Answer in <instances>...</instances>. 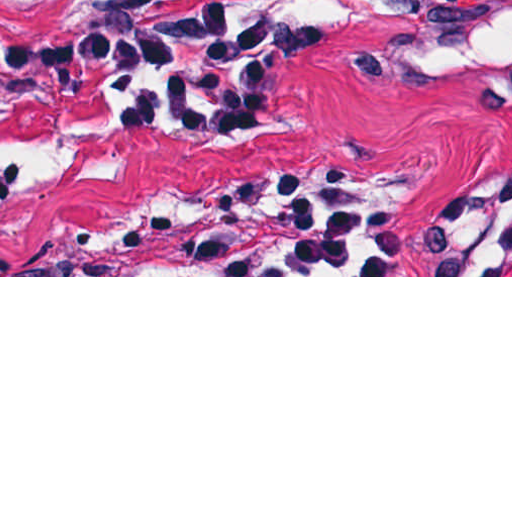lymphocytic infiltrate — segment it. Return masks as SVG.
<instances>
[{"label":"lymphocytic infiltrate","instance_id":"obj_1","mask_svg":"<svg viewBox=\"0 0 512 512\" xmlns=\"http://www.w3.org/2000/svg\"><path fill=\"white\" fill-rule=\"evenodd\" d=\"M260 40L254 1L205 0L145 24L25 37L6 64L20 86L46 100L88 93L186 129H225L257 103Z\"/></svg>","mask_w":512,"mask_h":512}]
</instances>
